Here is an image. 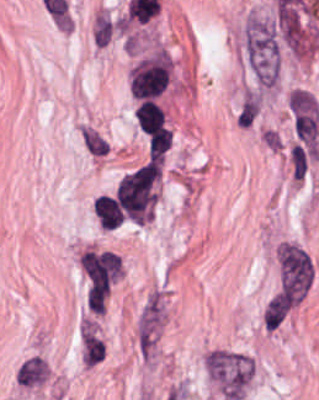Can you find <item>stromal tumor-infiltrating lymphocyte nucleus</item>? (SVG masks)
<instances>
[{"label":"stromal tumor-infiltrating lymphocyte nucleus","mask_w":319,"mask_h":400,"mask_svg":"<svg viewBox=\"0 0 319 400\" xmlns=\"http://www.w3.org/2000/svg\"><path fill=\"white\" fill-rule=\"evenodd\" d=\"M171 143L168 127H159L148 136L149 157L151 160H163Z\"/></svg>","instance_id":"obj_3"},{"label":"stromal tumor-infiltrating lymphocyte nucleus","mask_w":319,"mask_h":400,"mask_svg":"<svg viewBox=\"0 0 319 400\" xmlns=\"http://www.w3.org/2000/svg\"><path fill=\"white\" fill-rule=\"evenodd\" d=\"M135 115L144 135L148 136L157 131L164 122L163 109L154 100L142 99Z\"/></svg>","instance_id":"obj_2"},{"label":"stromal tumor-infiltrating lymphocyte nucleus","mask_w":319,"mask_h":400,"mask_svg":"<svg viewBox=\"0 0 319 400\" xmlns=\"http://www.w3.org/2000/svg\"><path fill=\"white\" fill-rule=\"evenodd\" d=\"M94 208L104 230H113L121 225L122 210L113 196L100 194L94 203Z\"/></svg>","instance_id":"obj_1"}]
</instances>
